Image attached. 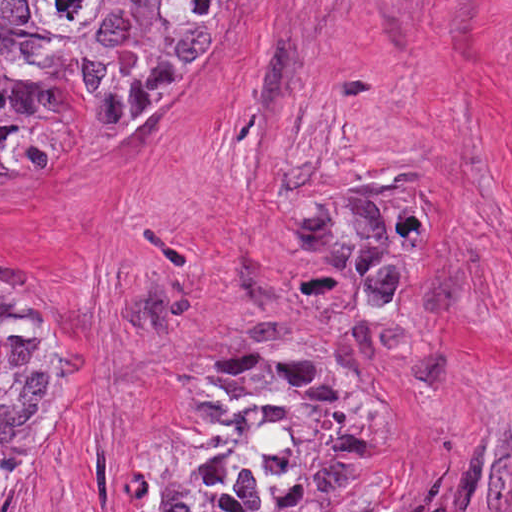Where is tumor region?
Segmentation results:
<instances>
[{
  "mask_svg": "<svg viewBox=\"0 0 512 512\" xmlns=\"http://www.w3.org/2000/svg\"><path fill=\"white\" fill-rule=\"evenodd\" d=\"M224 0H0V177L55 163L44 94L70 74L90 134L117 154L171 145L206 84ZM337 308L283 347L236 344L194 372L171 410L160 512H354L374 455V406L338 360L348 331L417 261V204L370 198L320 230ZM61 383L47 318L0 283V512Z\"/></svg>",
  "mask_w": 512,
  "mask_h": 512,
  "instance_id": "obj_1",
  "label": "tumor region"
}]
</instances>
